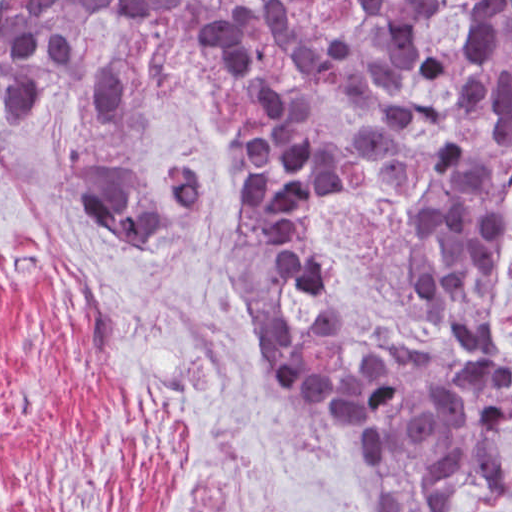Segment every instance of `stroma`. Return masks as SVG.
<instances>
[{"instance_id": "35a3bbf8", "label": "stroma", "mask_w": 512, "mask_h": 512, "mask_svg": "<svg viewBox=\"0 0 512 512\" xmlns=\"http://www.w3.org/2000/svg\"><path fill=\"white\" fill-rule=\"evenodd\" d=\"M160 52L108 16L30 123L0 107V512H352L342 453L239 302V195L209 103L180 77L123 120L85 115L95 75ZM98 167L152 195L193 170L207 202L138 261L73 193L68 174ZM498 346L512 364V195ZM451 512H512V465Z\"/></svg>"}]
</instances>
